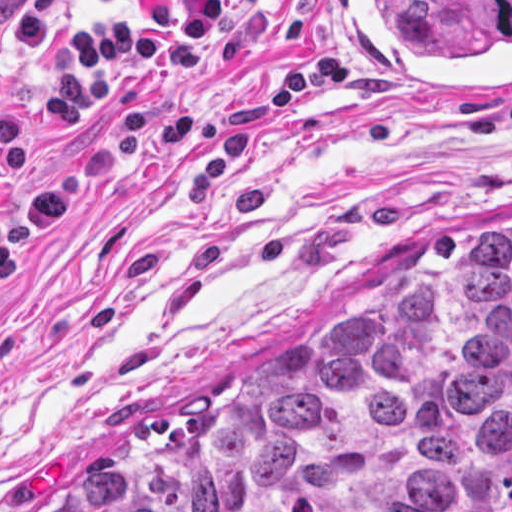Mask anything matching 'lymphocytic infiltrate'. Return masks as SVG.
<instances>
[{
  "mask_svg": "<svg viewBox=\"0 0 512 512\" xmlns=\"http://www.w3.org/2000/svg\"><path fill=\"white\" fill-rule=\"evenodd\" d=\"M256 0H123L121 20L67 24L69 0H0L2 36L24 54H51L43 108L63 127L80 125L94 105L111 107L102 141L66 175L27 194L33 128L0 101V286L39 247L64 213L104 180L113 161L134 151L163 157L191 130L186 104L154 109L173 72L211 73L238 54L236 32ZM281 1V0H261Z\"/></svg>",
  "mask_w": 512,
  "mask_h": 512,
  "instance_id": "obj_1",
  "label": "lymphocytic infiltrate"
}]
</instances>
